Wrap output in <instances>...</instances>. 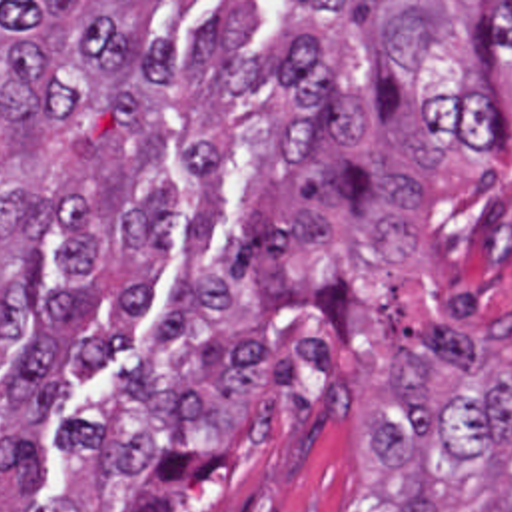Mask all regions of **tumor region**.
Returning a JSON list of instances; mask_svg holds the SVG:
<instances>
[{
    "instance_id": "obj_1",
    "label": "tumor region",
    "mask_w": 512,
    "mask_h": 512,
    "mask_svg": "<svg viewBox=\"0 0 512 512\" xmlns=\"http://www.w3.org/2000/svg\"><path fill=\"white\" fill-rule=\"evenodd\" d=\"M296 38L270 64L294 120L246 184L232 250L260 295L310 305L342 345L356 301L342 271L314 283L280 264L320 254L368 208L374 293L416 343L390 351L372 475L398 512H512V40L466 2H286ZM176 38L104 2H0V238L28 234L0 275V471L18 493L66 371L122 353L148 277L90 289L98 266L176 248V152L162 104Z\"/></svg>"
}]
</instances>
